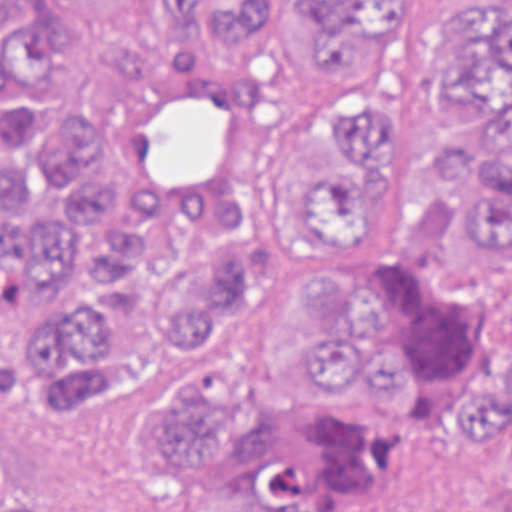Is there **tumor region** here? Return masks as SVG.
Wrapping results in <instances>:
<instances>
[{
	"label": "tumor region",
	"instance_id": "1",
	"mask_svg": "<svg viewBox=\"0 0 512 512\" xmlns=\"http://www.w3.org/2000/svg\"><path fill=\"white\" fill-rule=\"evenodd\" d=\"M384 0H166L163 19L227 38L250 57L298 19L347 40ZM444 48L455 100L476 116L455 137L443 197L391 213L386 94L331 72L271 142L303 246L261 283L250 340L282 389L256 402L234 361L255 263L245 216L215 199L184 215L127 198L117 173L139 88L82 109L61 89L56 32L32 9L0 29V357L16 329L72 395H128L193 340L144 422L165 478L200 500L259 512H335L380 460L453 417L512 448V374L465 346L512 318L439 297L393 260L366 257L379 217L432 215L471 185L468 134L491 131L468 217L512 252V0H453ZM44 488L0 458V512H50Z\"/></svg>",
	"mask_w": 512,
	"mask_h": 512
}]
</instances>
